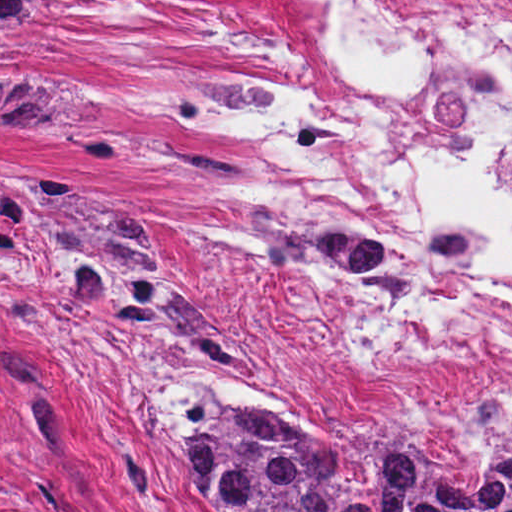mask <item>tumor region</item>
Wrapping results in <instances>:
<instances>
[{
    "instance_id": "obj_1",
    "label": "tumor region",
    "mask_w": 512,
    "mask_h": 512,
    "mask_svg": "<svg viewBox=\"0 0 512 512\" xmlns=\"http://www.w3.org/2000/svg\"><path fill=\"white\" fill-rule=\"evenodd\" d=\"M71 0H0V106L60 118L76 96L30 74L11 55L26 29ZM223 79H193L154 97L185 123H199L201 95ZM82 159L123 152L176 155L219 184L233 180L221 158L133 131H53ZM28 208L39 237L63 256L81 300L120 324L164 333L176 322L184 288L149 238L101 187L66 171L24 169ZM239 205V204H238ZM252 240L269 261L346 267L405 293L382 248L346 233H301L249 217ZM152 415L168 426L177 460L206 512H512V429L467 478L424 457L394 423L343 446L307 431L281 411L227 397L188 379L160 391Z\"/></svg>"
}]
</instances>
